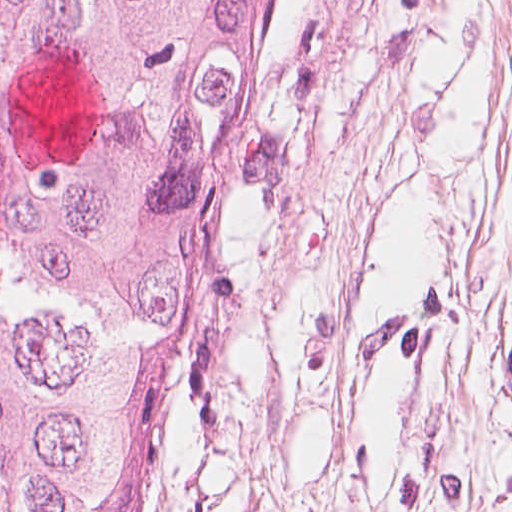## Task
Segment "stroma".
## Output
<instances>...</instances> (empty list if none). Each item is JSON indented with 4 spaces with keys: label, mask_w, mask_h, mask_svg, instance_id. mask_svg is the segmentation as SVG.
Wrapping results in <instances>:
<instances>
[{
    "label": "stroma",
    "mask_w": 512,
    "mask_h": 512,
    "mask_svg": "<svg viewBox=\"0 0 512 512\" xmlns=\"http://www.w3.org/2000/svg\"><path fill=\"white\" fill-rule=\"evenodd\" d=\"M314 0H286L195 328L166 355L139 460L145 512H206Z\"/></svg>",
    "instance_id": "stroma-1"
}]
</instances>
